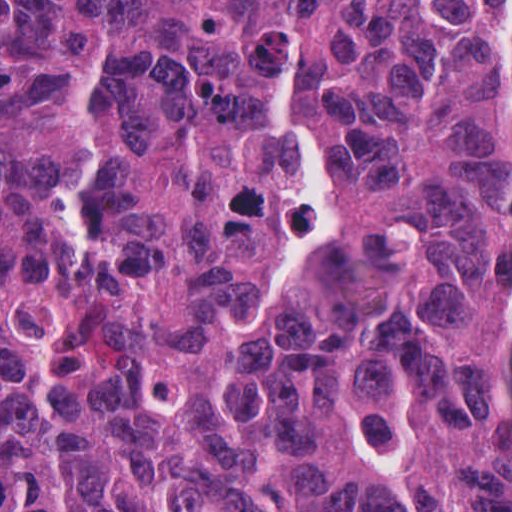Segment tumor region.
I'll list each match as a JSON object with an SVG mask.
<instances>
[{
  "mask_svg": "<svg viewBox=\"0 0 512 512\" xmlns=\"http://www.w3.org/2000/svg\"><path fill=\"white\" fill-rule=\"evenodd\" d=\"M512 1H0V512H512Z\"/></svg>",
  "mask_w": 512,
  "mask_h": 512,
  "instance_id": "1",
  "label": "tumor region"
}]
</instances>
